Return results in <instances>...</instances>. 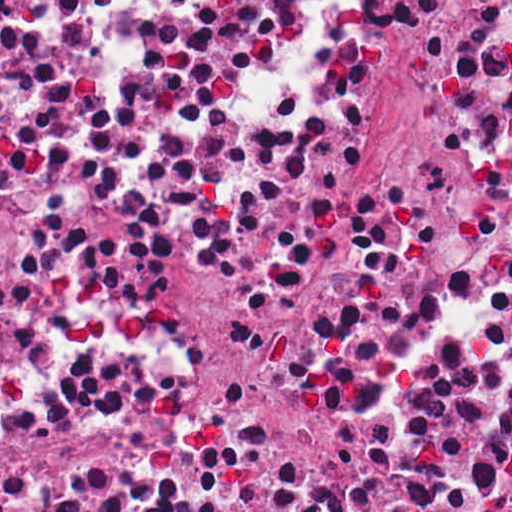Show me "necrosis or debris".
Masks as SVG:
<instances>
[{"mask_svg": "<svg viewBox=\"0 0 512 512\" xmlns=\"http://www.w3.org/2000/svg\"><path fill=\"white\" fill-rule=\"evenodd\" d=\"M0 512H512V0H0Z\"/></svg>", "mask_w": 512, "mask_h": 512, "instance_id": "necrosis-or-debris-1", "label": "necrosis or debris"}]
</instances>
